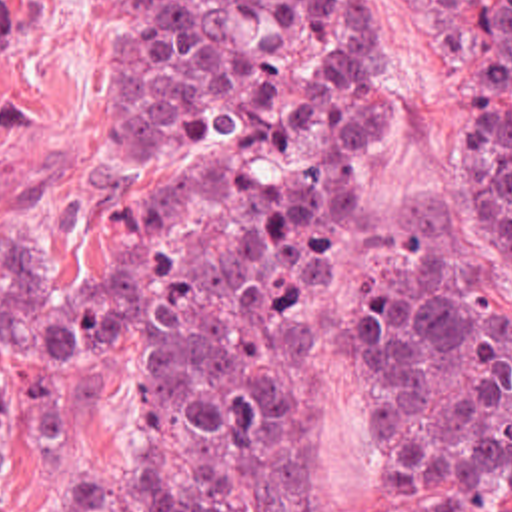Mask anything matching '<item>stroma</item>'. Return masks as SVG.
Here are the masks:
<instances>
[{
  "instance_id": "obj_1",
  "label": "stroma",
  "mask_w": 512,
  "mask_h": 512,
  "mask_svg": "<svg viewBox=\"0 0 512 512\" xmlns=\"http://www.w3.org/2000/svg\"><path fill=\"white\" fill-rule=\"evenodd\" d=\"M367 40L355 149L333 181L303 271V373L311 409V512H387L401 501L512 512V463L397 467L381 455L359 357V289L381 261L453 255L512 299V221L473 163L481 88L475 0H351ZM87 40L45 50L37 82L0 100V225L33 245L91 247L99 233V90ZM71 453L59 481L0 467L5 512H61L95 463L137 455L135 369L121 341L55 357ZM0 459L23 473L59 461L57 421L19 351L0 345Z\"/></svg>"
}]
</instances>
